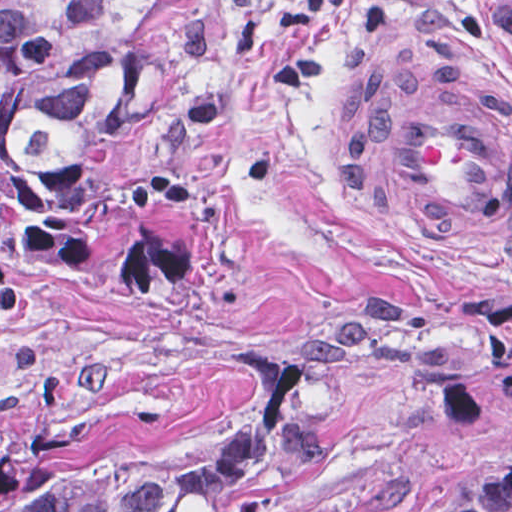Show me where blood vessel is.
Returning <instances> with one entry per match:
<instances>
[{
    "instance_id": "obj_1",
    "label": "blood vessel",
    "mask_w": 512,
    "mask_h": 512,
    "mask_svg": "<svg viewBox=\"0 0 512 512\" xmlns=\"http://www.w3.org/2000/svg\"><path fill=\"white\" fill-rule=\"evenodd\" d=\"M454 59L357 93L351 174L369 215L411 257L502 263L512 257V112L438 69Z\"/></svg>"
}]
</instances>
